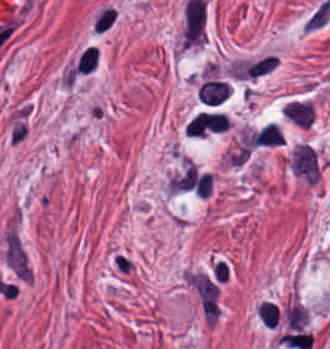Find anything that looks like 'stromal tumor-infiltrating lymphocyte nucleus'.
Masks as SVG:
<instances>
[{
	"instance_id": "obj_4",
	"label": "stromal tumor-infiltrating lymphocyte nucleus",
	"mask_w": 330,
	"mask_h": 349,
	"mask_svg": "<svg viewBox=\"0 0 330 349\" xmlns=\"http://www.w3.org/2000/svg\"><path fill=\"white\" fill-rule=\"evenodd\" d=\"M99 51L95 46H88L77 60L76 69L79 73H88L95 69Z\"/></svg>"
},
{
	"instance_id": "obj_2",
	"label": "stromal tumor-infiltrating lymphocyte nucleus",
	"mask_w": 330,
	"mask_h": 349,
	"mask_svg": "<svg viewBox=\"0 0 330 349\" xmlns=\"http://www.w3.org/2000/svg\"><path fill=\"white\" fill-rule=\"evenodd\" d=\"M283 141V132L276 122L269 121L257 131L256 146H278Z\"/></svg>"
},
{
	"instance_id": "obj_3",
	"label": "stromal tumor-infiltrating lymphocyte nucleus",
	"mask_w": 330,
	"mask_h": 349,
	"mask_svg": "<svg viewBox=\"0 0 330 349\" xmlns=\"http://www.w3.org/2000/svg\"><path fill=\"white\" fill-rule=\"evenodd\" d=\"M257 314L263 325L276 327L279 319L280 309L278 304L269 300H262L258 304Z\"/></svg>"
},
{
	"instance_id": "obj_1",
	"label": "stromal tumor-infiltrating lymphocyte nucleus",
	"mask_w": 330,
	"mask_h": 349,
	"mask_svg": "<svg viewBox=\"0 0 330 349\" xmlns=\"http://www.w3.org/2000/svg\"><path fill=\"white\" fill-rule=\"evenodd\" d=\"M116 18L115 5L106 0L96 8L90 20V30L101 35L111 29Z\"/></svg>"
}]
</instances>
